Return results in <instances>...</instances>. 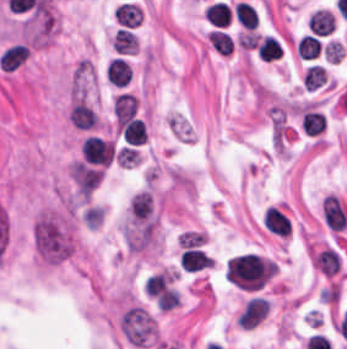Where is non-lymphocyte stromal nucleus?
I'll return each mask as SVG.
<instances>
[{
	"instance_id": "obj_1",
	"label": "non-lymphocyte stromal nucleus",
	"mask_w": 347,
	"mask_h": 349,
	"mask_svg": "<svg viewBox=\"0 0 347 349\" xmlns=\"http://www.w3.org/2000/svg\"><path fill=\"white\" fill-rule=\"evenodd\" d=\"M34 242L47 264H59L73 253L57 225L43 214L34 226Z\"/></svg>"
},
{
	"instance_id": "obj_2",
	"label": "non-lymphocyte stromal nucleus",
	"mask_w": 347,
	"mask_h": 349,
	"mask_svg": "<svg viewBox=\"0 0 347 349\" xmlns=\"http://www.w3.org/2000/svg\"><path fill=\"white\" fill-rule=\"evenodd\" d=\"M322 210L330 230L343 231L345 229L347 226V211L337 196L327 194L322 204Z\"/></svg>"
},
{
	"instance_id": "obj_3",
	"label": "non-lymphocyte stromal nucleus",
	"mask_w": 347,
	"mask_h": 349,
	"mask_svg": "<svg viewBox=\"0 0 347 349\" xmlns=\"http://www.w3.org/2000/svg\"><path fill=\"white\" fill-rule=\"evenodd\" d=\"M92 78L90 64L86 60H79L73 75L71 104L85 99Z\"/></svg>"
}]
</instances>
